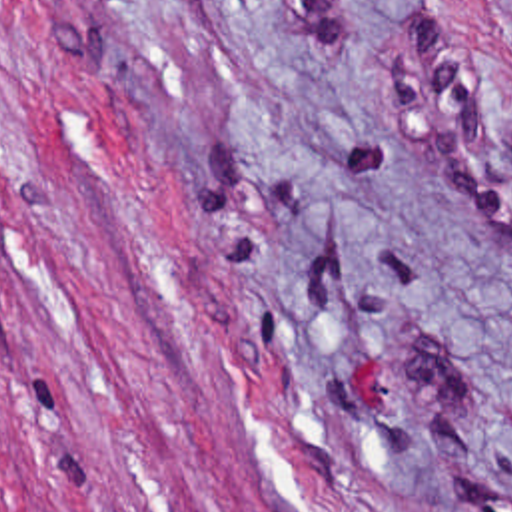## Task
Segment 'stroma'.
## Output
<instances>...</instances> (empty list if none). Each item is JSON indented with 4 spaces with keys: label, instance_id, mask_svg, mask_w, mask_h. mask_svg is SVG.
<instances>
[{
    "label": "stroma",
    "instance_id": "1",
    "mask_svg": "<svg viewBox=\"0 0 512 512\" xmlns=\"http://www.w3.org/2000/svg\"><path fill=\"white\" fill-rule=\"evenodd\" d=\"M0 512H512V0H0Z\"/></svg>",
    "mask_w": 512,
    "mask_h": 512
}]
</instances>
